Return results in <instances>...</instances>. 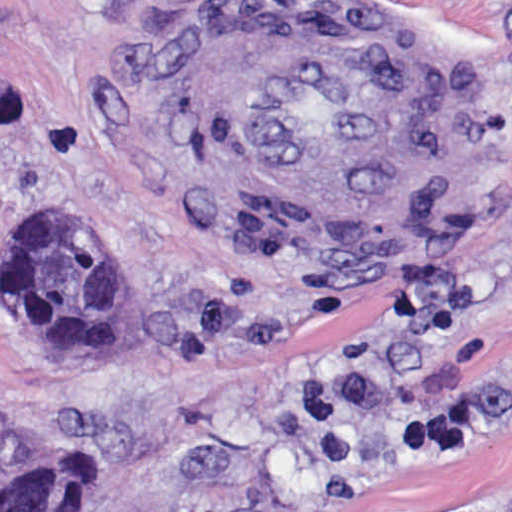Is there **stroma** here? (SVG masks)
I'll list each match as a JSON object with an SVG mask.
<instances>
[{
    "label": "stroma",
    "instance_id": "obj_1",
    "mask_svg": "<svg viewBox=\"0 0 512 512\" xmlns=\"http://www.w3.org/2000/svg\"><path fill=\"white\" fill-rule=\"evenodd\" d=\"M238 9L381 49L404 189L371 229H297L243 168L209 87ZM34 203L106 235L114 355L18 331ZM56 437L93 512H512V0H0V453Z\"/></svg>",
    "mask_w": 512,
    "mask_h": 512
}]
</instances>
